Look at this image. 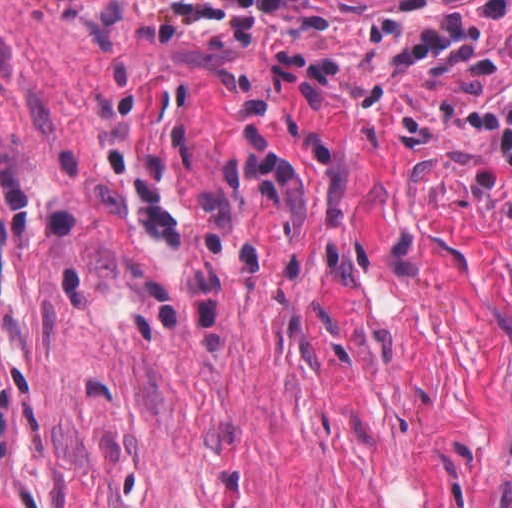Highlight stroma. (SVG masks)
Listing matches in <instances>:
<instances>
[{
    "mask_svg": "<svg viewBox=\"0 0 512 512\" xmlns=\"http://www.w3.org/2000/svg\"><path fill=\"white\" fill-rule=\"evenodd\" d=\"M32 0H0V19Z\"/></svg>",
    "mask_w": 512,
    "mask_h": 512,
    "instance_id": "stroma-1",
    "label": "stroma"
}]
</instances>
